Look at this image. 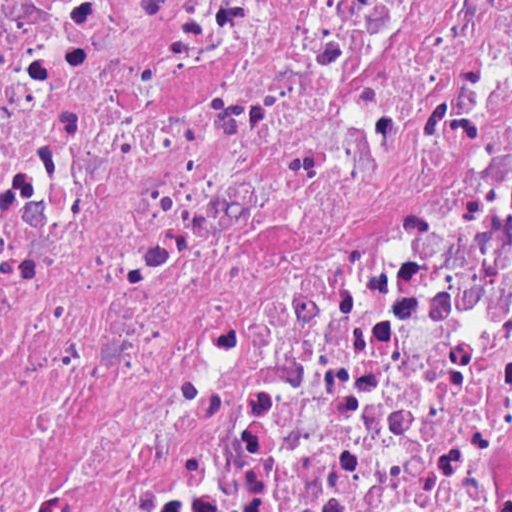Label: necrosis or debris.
<instances>
[{"mask_svg": "<svg viewBox=\"0 0 512 512\" xmlns=\"http://www.w3.org/2000/svg\"><path fill=\"white\" fill-rule=\"evenodd\" d=\"M0 512H512V0H0Z\"/></svg>", "mask_w": 512, "mask_h": 512, "instance_id": "1", "label": "necrosis or debris"}]
</instances>
